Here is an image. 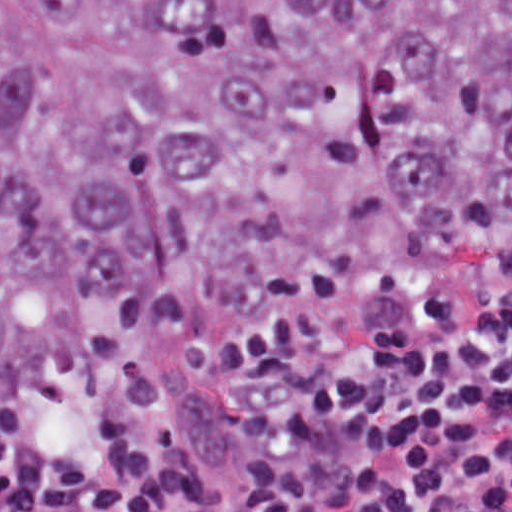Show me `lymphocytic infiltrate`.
<instances>
[{
	"label": "lymphocytic infiltrate",
	"instance_id": "obj_1",
	"mask_svg": "<svg viewBox=\"0 0 512 512\" xmlns=\"http://www.w3.org/2000/svg\"><path fill=\"white\" fill-rule=\"evenodd\" d=\"M0 512H512V303L321 319L1 411Z\"/></svg>",
	"mask_w": 512,
	"mask_h": 512
}]
</instances>
